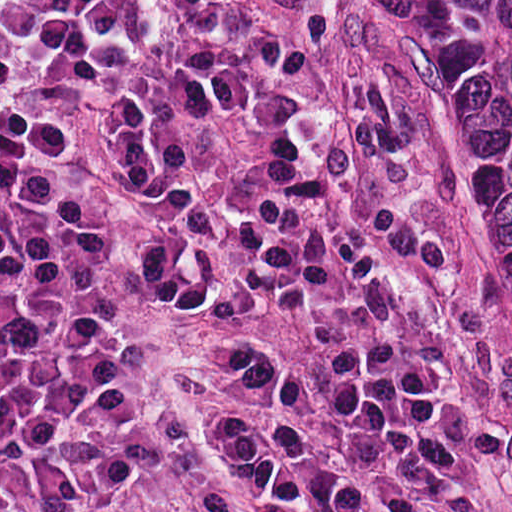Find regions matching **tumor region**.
I'll return each instance as SVG.
<instances>
[{
    "instance_id": "tumor-region-1",
    "label": "tumor region",
    "mask_w": 512,
    "mask_h": 512,
    "mask_svg": "<svg viewBox=\"0 0 512 512\" xmlns=\"http://www.w3.org/2000/svg\"><path fill=\"white\" fill-rule=\"evenodd\" d=\"M422 153L512 325V0H359Z\"/></svg>"
}]
</instances>
